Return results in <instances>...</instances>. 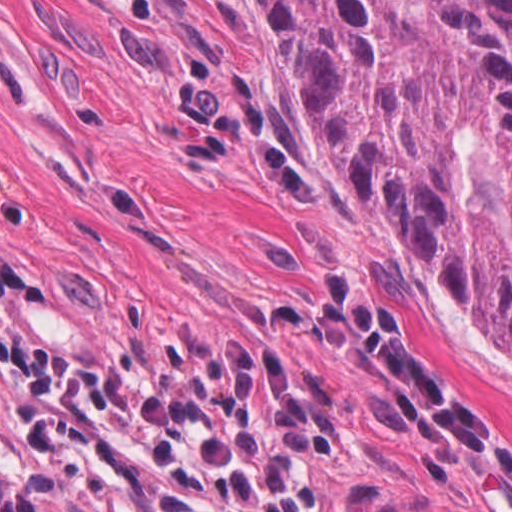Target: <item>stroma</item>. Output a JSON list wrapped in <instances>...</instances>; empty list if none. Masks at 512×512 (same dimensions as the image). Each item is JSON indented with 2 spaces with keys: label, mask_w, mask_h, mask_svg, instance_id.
<instances>
[{
  "label": "stroma",
  "mask_w": 512,
  "mask_h": 512,
  "mask_svg": "<svg viewBox=\"0 0 512 512\" xmlns=\"http://www.w3.org/2000/svg\"><path fill=\"white\" fill-rule=\"evenodd\" d=\"M0 252L37 289L36 350L91 368L270 345L283 307L364 288L408 350L512 432V350L313 142L242 0H0ZM334 512H512V481L425 432L388 377L315 347ZM0 476L93 512L24 453L0 391Z\"/></svg>",
  "instance_id": "stroma-1"
}]
</instances>
